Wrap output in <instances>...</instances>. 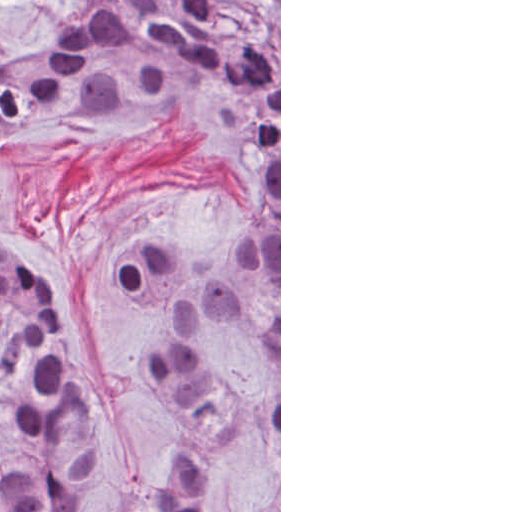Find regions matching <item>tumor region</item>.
I'll list each match as a JSON object with an SVG mask.
<instances>
[{
    "label": "tumor region",
    "mask_w": 512,
    "mask_h": 512,
    "mask_svg": "<svg viewBox=\"0 0 512 512\" xmlns=\"http://www.w3.org/2000/svg\"><path fill=\"white\" fill-rule=\"evenodd\" d=\"M120 114L192 126L267 187L240 243L269 301L266 318L219 280L188 273L180 254L188 239L145 236L116 263L121 291L169 320L140 359L187 413L180 447L128 512H205L235 464L237 414L218 329L279 367V39L270 21L252 5L231 12L215 0H95L63 45L0 65V186L10 157L39 133ZM14 248L0 241V406L15 433V451L0 460V512H109L65 313ZM248 512H279V492Z\"/></svg>",
    "instance_id": "tumor-region-1"
}]
</instances>
